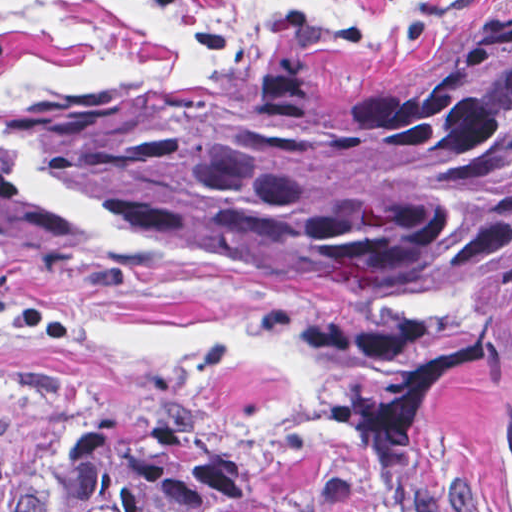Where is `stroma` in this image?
<instances>
[{"instance_id":"obj_1","label":"stroma","mask_w":512,"mask_h":512,"mask_svg":"<svg viewBox=\"0 0 512 512\" xmlns=\"http://www.w3.org/2000/svg\"><path fill=\"white\" fill-rule=\"evenodd\" d=\"M267 78H346L439 55L512 0H198ZM196 41L141 0H0V97L79 98L196 70ZM0 247V512L49 507L111 431L182 441L228 488L337 464L341 512H512L498 391H462L382 458L284 317L317 297Z\"/></svg>"}]
</instances>
